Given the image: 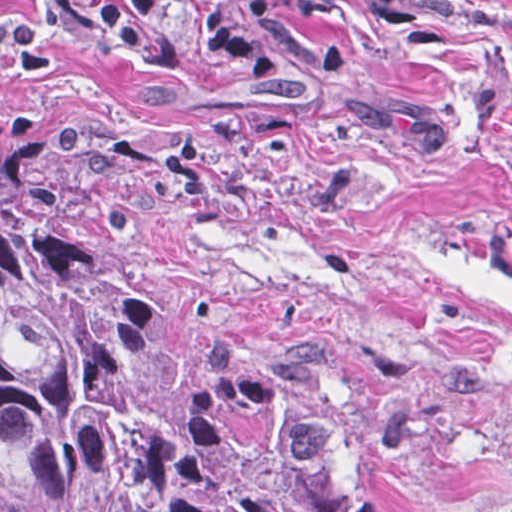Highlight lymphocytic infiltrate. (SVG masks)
Listing matches in <instances>:
<instances>
[{"label": "lymphocytic infiltrate", "instance_id": "f902f5d3", "mask_svg": "<svg viewBox=\"0 0 512 512\" xmlns=\"http://www.w3.org/2000/svg\"><path fill=\"white\" fill-rule=\"evenodd\" d=\"M58 23L112 60H138L160 45L155 16L180 4L255 84L270 80L266 50L230 0H47Z\"/></svg>", "mask_w": 512, "mask_h": 512}]
</instances>
